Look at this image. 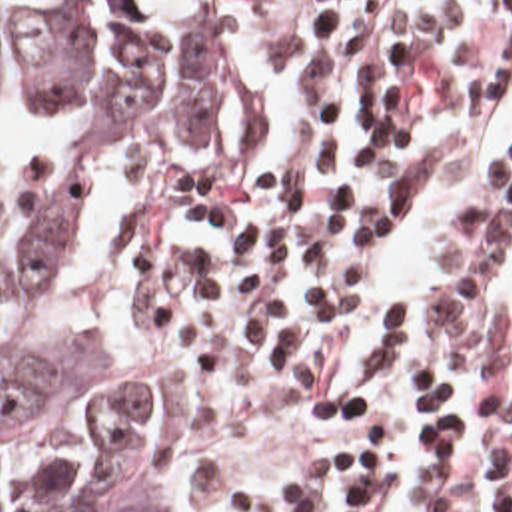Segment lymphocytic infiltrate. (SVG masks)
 Listing matches in <instances>:
<instances>
[{"label": "lymphocytic infiltrate", "mask_w": 512, "mask_h": 512, "mask_svg": "<svg viewBox=\"0 0 512 512\" xmlns=\"http://www.w3.org/2000/svg\"><path fill=\"white\" fill-rule=\"evenodd\" d=\"M512 0H429L327 28L249 76L165 212L151 364L203 509L253 420L303 402L309 468L239 512H379L383 422L331 374L433 160L507 80ZM415 442V512H512V144L421 302L375 354Z\"/></svg>", "instance_id": "f902f5d3"}]
</instances>
